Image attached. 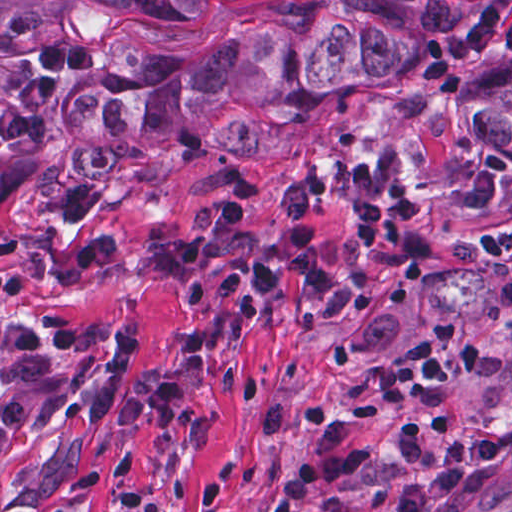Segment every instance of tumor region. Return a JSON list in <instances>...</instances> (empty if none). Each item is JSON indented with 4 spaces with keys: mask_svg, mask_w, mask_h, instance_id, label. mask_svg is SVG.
<instances>
[{
    "mask_svg": "<svg viewBox=\"0 0 512 512\" xmlns=\"http://www.w3.org/2000/svg\"><path fill=\"white\" fill-rule=\"evenodd\" d=\"M124 18H187L198 0H90ZM473 0H272L201 54L120 47L106 72L71 98L92 143L78 151L86 177L109 181L146 157L168 132L241 155L286 154L260 127L281 118L298 127L320 119L327 97L376 83H409L438 39L480 12ZM472 140L512 152V72L486 78L466 100Z\"/></svg>",
    "mask_w": 512,
    "mask_h": 512,
    "instance_id": "e687c5a6",
    "label": "tumor region"
}]
</instances>
